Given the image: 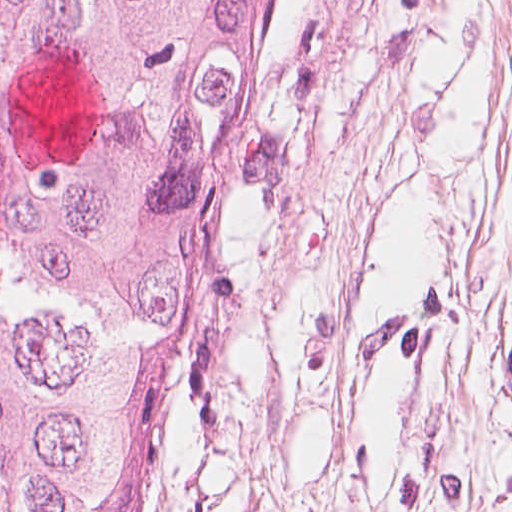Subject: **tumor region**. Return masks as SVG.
Segmentation results:
<instances>
[{
  "label": "tumor region",
  "mask_w": 512,
  "mask_h": 512,
  "mask_svg": "<svg viewBox=\"0 0 512 512\" xmlns=\"http://www.w3.org/2000/svg\"><path fill=\"white\" fill-rule=\"evenodd\" d=\"M286 0H0V512H145Z\"/></svg>",
  "instance_id": "e687c5a6"
}]
</instances>
